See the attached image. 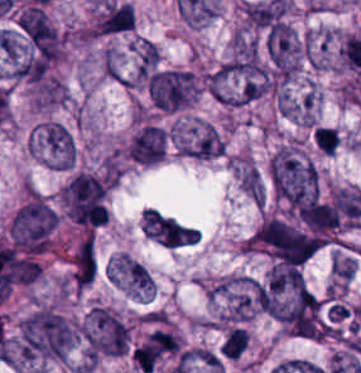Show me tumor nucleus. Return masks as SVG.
I'll use <instances>...</instances> for the list:
<instances>
[{
	"label": "tumor nucleus",
	"mask_w": 361,
	"mask_h": 373,
	"mask_svg": "<svg viewBox=\"0 0 361 373\" xmlns=\"http://www.w3.org/2000/svg\"><path fill=\"white\" fill-rule=\"evenodd\" d=\"M112 281L139 299L141 292L114 256L110 261Z\"/></svg>",
	"instance_id": "1edb0cf7"
},
{
	"label": "tumor nucleus",
	"mask_w": 361,
	"mask_h": 373,
	"mask_svg": "<svg viewBox=\"0 0 361 373\" xmlns=\"http://www.w3.org/2000/svg\"><path fill=\"white\" fill-rule=\"evenodd\" d=\"M58 220L42 198L29 197L13 214L8 227L11 244L30 255H38L52 246Z\"/></svg>",
	"instance_id": "5ab6c2c4"
},
{
	"label": "tumor nucleus",
	"mask_w": 361,
	"mask_h": 373,
	"mask_svg": "<svg viewBox=\"0 0 361 373\" xmlns=\"http://www.w3.org/2000/svg\"><path fill=\"white\" fill-rule=\"evenodd\" d=\"M78 329L86 357L90 360L121 355L130 349V327L106 306L95 303Z\"/></svg>",
	"instance_id": "8643909e"
},
{
	"label": "tumor nucleus",
	"mask_w": 361,
	"mask_h": 373,
	"mask_svg": "<svg viewBox=\"0 0 361 373\" xmlns=\"http://www.w3.org/2000/svg\"><path fill=\"white\" fill-rule=\"evenodd\" d=\"M178 351V336L165 327H158L131 347L130 359L132 365L140 371L152 373Z\"/></svg>",
	"instance_id": "2083b535"
},
{
	"label": "tumor nucleus",
	"mask_w": 361,
	"mask_h": 373,
	"mask_svg": "<svg viewBox=\"0 0 361 373\" xmlns=\"http://www.w3.org/2000/svg\"><path fill=\"white\" fill-rule=\"evenodd\" d=\"M265 53L273 77L286 81L298 67L302 46L295 31L275 18L265 28Z\"/></svg>",
	"instance_id": "3d1891a8"
},
{
	"label": "tumor nucleus",
	"mask_w": 361,
	"mask_h": 373,
	"mask_svg": "<svg viewBox=\"0 0 361 373\" xmlns=\"http://www.w3.org/2000/svg\"><path fill=\"white\" fill-rule=\"evenodd\" d=\"M11 76L36 81L57 62L61 37L40 4H27L1 33Z\"/></svg>",
	"instance_id": "2f306a5c"
},
{
	"label": "tumor nucleus",
	"mask_w": 361,
	"mask_h": 373,
	"mask_svg": "<svg viewBox=\"0 0 361 373\" xmlns=\"http://www.w3.org/2000/svg\"><path fill=\"white\" fill-rule=\"evenodd\" d=\"M247 344V331L242 328L233 329L224 339L220 346L224 356L238 357Z\"/></svg>",
	"instance_id": "268c6acd"
},
{
	"label": "tumor nucleus",
	"mask_w": 361,
	"mask_h": 373,
	"mask_svg": "<svg viewBox=\"0 0 361 373\" xmlns=\"http://www.w3.org/2000/svg\"><path fill=\"white\" fill-rule=\"evenodd\" d=\"M134 28V14L130 5L121 1H107L95 19L91 30L97 35L126 33Z\"/></svg>",
	"instance_id": "3e47fb67"
},
{
	"label": "tumor nucleus",
	"mask_w": 361,
	"mask_h": 373,
	"mask_svg": "<svg viewBox=\"0 0 361 373\" xmlns=\"http://www.w3.org/2000/svg\"><path fill=\"white\" fill-rule=\"evenodd\" d=\"M64 216L86 227L105 223L106 184L95 174L75 173L61 189Z\"/></svg>",
	"instance_id": "2cbd58db"
},
{
	"label": "tumor nucleus",
	"mask_w": 361,
	"mask_h": 373,
	"mask_svg": "<svg viewBox=\"0 0 361 373\" xmlns=\"http://www.w3.org/2000/svg\"><path fill=\"white\" fill-rule=\"evenodd\" d=\"M227 68L231 73L249 81L261 74L256 43L252 35L244 30H236L232 35Z\"/></svg>",
	"instance_id": "feef74b5"
},
{
	"label": "tumor nucleus",
	"mask_w": 361,
	"mask_h": 373,
	"mask_svg": "<svg viewBox=\"0 0 361 373\" xmlns=\"http://www.w3.org/2000/svg\"><path fill=\"white\" fill-rule=\"evenodd\" d=\"M312 141L322 153L331 154L338 146V131L329 125H316L312 133Z\"/></svg>",
	"instance_id": "f7901128"
},
{
	"label": "tumor nucleus",
	"mask_w": 361,
	"mask_h": 373,
	"mask_svg": "<svg viewBox=\"0 0 361 373\" xmlns=\"http://www.w3.org/2000/svg\"><path fill=\"white\" fill-rule=\"evenodd\" d=\"M32 144L51 167H72L73 141L64 125L42 121L32 133Z\"/></svg>",
	"instance_id": "8087334f"
},
{
	"label": "tumor nucleus",
	"mask_w": 361,
	"mask_h": 373,
	"mask_svg": "<svg viewBox=\"0 0 361 373\" xmlns=\"http://www.w3.org/2000/svg\"><path fill=\"white\" fill-rule=\"evenodd\" d=\"M125 152L129 159L140 165H151L165 154L163 126L144 123L130 138Z\"/></svg>",
	"instance_id": "c2bd9aea"
}]
</instances>
